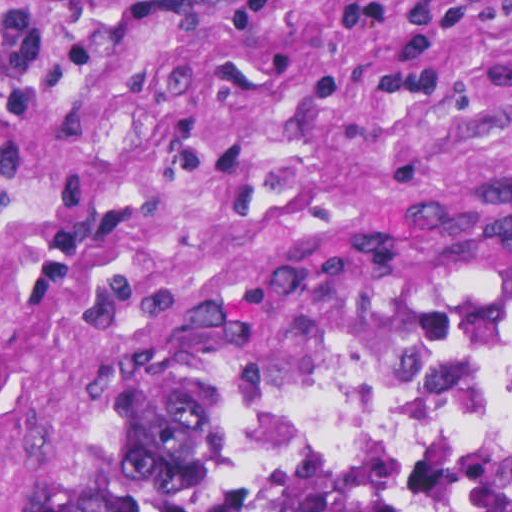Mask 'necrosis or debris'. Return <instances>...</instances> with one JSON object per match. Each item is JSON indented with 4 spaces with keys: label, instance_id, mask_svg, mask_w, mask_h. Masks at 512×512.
Instances as JSON below:
<instances>
[{
    "label": "necrosis or debris",
    "instance_id": "1",
    "mask_svg": "<svg viewBox=\"0 0 512 512\" xmlns=\"http://www.w3.org/2000/svg\"><path fill=\"white\" fill-rule=\"evenodd\" d=\"M278 428L307 444L439 446L512 460V306L378 325L322 352L281 402ZM101 512L424 511L261 486H175L120 494Z\"/></svg>",
    "mask_w": 512,
    "mask_h": 512
}]
</instances>
